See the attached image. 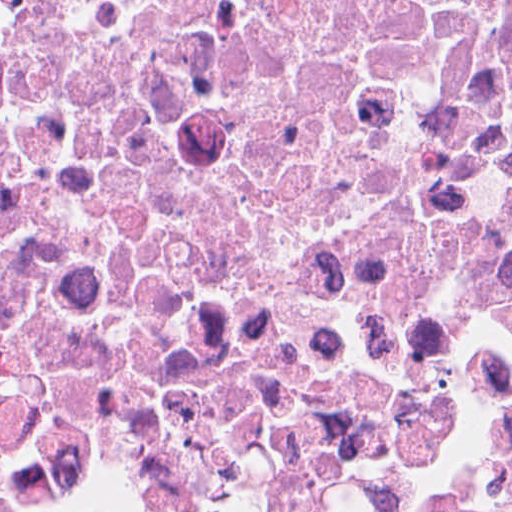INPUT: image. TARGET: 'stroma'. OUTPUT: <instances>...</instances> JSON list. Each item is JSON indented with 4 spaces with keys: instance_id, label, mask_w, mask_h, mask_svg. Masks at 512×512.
<instances>
[{
    "instance_id": "35a3bbf8",
    "label": "stroma",
    "mask_w": 512,
    "mask_h": 512,
    "mask_svg": "<svg viewBox=\"0 0 512 512\" xmlns=\"http://www.w3.org/2000/svg\"><path fill=\"white\" fill-rule=\"evenodd\" d=\"M504 451L505 449L499 455L496 463L494 464L488 478L486 490L481 496L498 487ZM0 505L15 510H89L84 508H78L68 503L67 501L59 498L45 486L29 482L11 480L3 477H0Z\"/></svg>"
}]
</instances>
